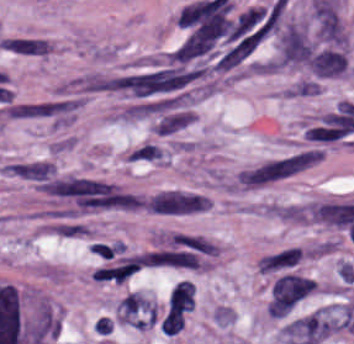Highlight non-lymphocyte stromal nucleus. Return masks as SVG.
<instances>
[{
	"label": "non-lymphocyte stromal nucleus",
	"instance_id": "dd21d789",
	"mask_svg": "<svg viewBox=\"0 0 354 344\" xmlns=\"http://www.w3.org/2000/svg\"><path fill=\"white\" fill-rule=\"evenodd\" d=\"M311 148H298L243 164L230 180L231 187L260 189L301 173L318 163Z\"/></svg>",
	"mask_w": 354,
	"mask_h": 344
},
{
	"label": "non-lymphocyte stromal nucleus",
	"instance_id": "a72fc3eb",
	"mask_svg": "<svg viewBox=\"0 0 354 344\" xmlns=\"http://www.w3.org/2000/svg\"><path fill=\"white\" fill-rule=\"evenodd\" d=\"M312 291V279L285 273L279 275L267 306L270 316H285Z\"/></svg>",
	"mask_w": 354,
	"mask_h": 344
},
{
	"label": "non-lymphocyte stromal nucleus",
	"instance_id": "3746e769",
	"mask_svg": "<svg viewBox=\"0 0 354 344\" xmlns=\"http://www.w3.org/2000/svg\"><path fill=\"white\" fill-rule=\"evenodd\" d=\"M207 200L188 190H162L148 195L143 208L167 215H184L201 210Z\"/></svg>",
	"mask_w": 354,
	"mask_h": 344
},
{
	"label": "non-lymphocyte stromal nucleus",
	"instance_id": "fc2b8d12",
	"mask_svg": "<svg viewBox=\"0 0 354 344\" xmlns=\"http://www.w3.org/2000/svg\"><path fill=\"white\" fill-rule=\"evenodd\" d=\"M115 307L120 321L136 328H146L154 322L157 314L154 301L133 290L125 294Z\"/></svg>",
	"mask_w": 354,
	"mask_h": 344
},
{
	"label": "non-lymphocyte stromal nucleus",
	"instance_id": "81446118",
	"mask_svg": "<svg viewBox=\"0 0 354 344\" xmlns=\"http://www.w3.org/2000/svg\"><path fill=\"white\" fill-rule=\"evenodd\" d=\"M313 200L274 201L264 207L266 215L284 222L310 223Z\"/></svg>",
	"mask_w": 354,
	"mask_h": 344
},
{
	"label": "non-lymphocyte stromal nucleus",
	"instance_id": "7c5642bf",
	"mask_svg": "<svg viewBox=\"0 0 354 344\" xmlns=\"http://www.w3.org/2000/svg\"><path fill=\"white\" fill-rule=\"evenodd\" d=\"M300 253L297 247L283 249L263 258H259V273H269L272 271L287 268L299 260Z\"/></svg>",
	"mask_w": 354,
	"mask_h": 344
}]
</instances>
